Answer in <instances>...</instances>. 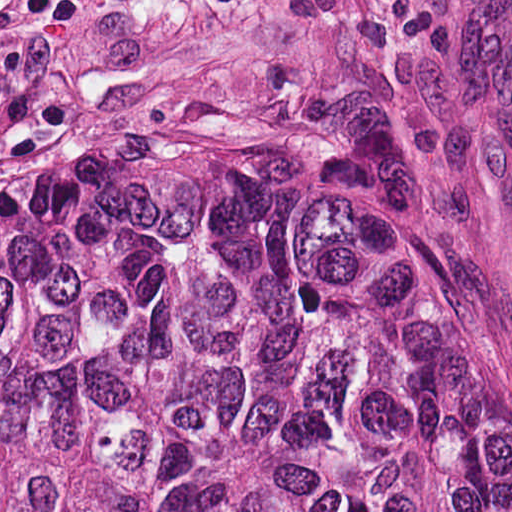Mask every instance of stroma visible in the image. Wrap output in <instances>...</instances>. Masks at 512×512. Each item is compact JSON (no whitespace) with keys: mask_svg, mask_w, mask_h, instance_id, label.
Returning a JSON list of instances; mask_svg holds the SVG:
<instances>
[{"mask_svg":"<svg viewBox=\"0 0 512 512\" xmlns=\"http://www.w3.org/2000/svg\"><path fill=\"white\" fill-rule=\"evenodd\" d=\"M0 0V178L85 128L330 149L451 238L512 396V0Z\"/></svg>","mask_w":512,"mask_h":512,"instance_id":"1","label":"stroma"}]
</instances>
